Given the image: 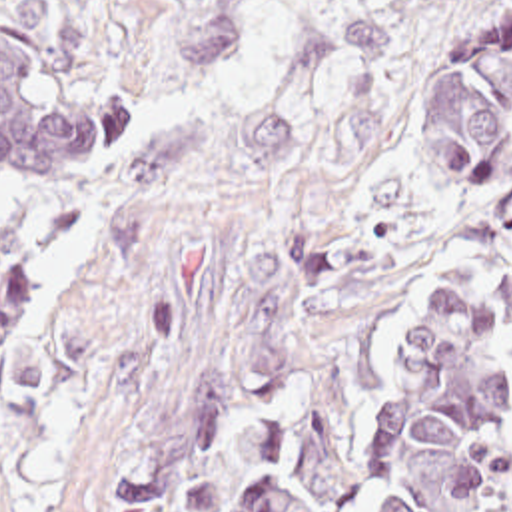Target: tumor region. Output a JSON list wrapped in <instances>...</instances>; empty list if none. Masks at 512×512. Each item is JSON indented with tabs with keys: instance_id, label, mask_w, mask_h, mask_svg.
<instances>
[{
	"instance_id": "e687c5a6",
	"label": "tumor region",
	"mask_w": 512,
	"mask_h": 512,
	"mask_svg": "<svg viewBox=\"0 0 512 512\" xmlns=\"http://www.w3.org/2000/svg\"><path fill=\"white\" fill-rule=\"evenodd\" d=\"M411 133L425 183L481 199L505 163L512 0H421ZM122 105L60 85L0 15V179L96 181ZM38 265L0 219V369L20 361ZM140 512H512V411L491 297L465 279L316 335L214 411Z\"/></svg>"
}]
</instances>
